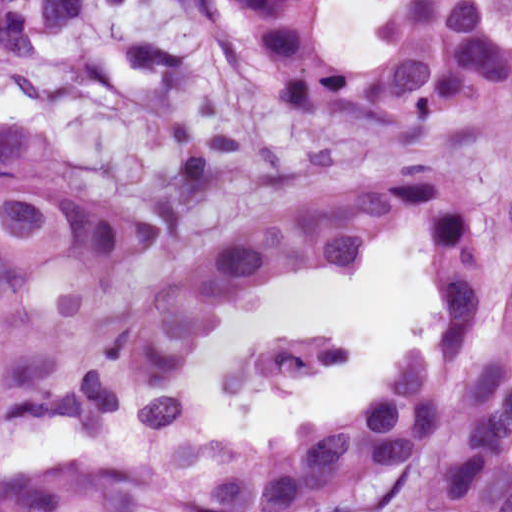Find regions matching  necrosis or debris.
I'll use <instances>...</instances> for the list:
<instances>
[{"label":"necrosis or debris","mask_w":512,"mask_h":512,"mask_svg":"<svg viewBox=\"0 0 512 512\" xmlns=\"http://www.w3.org/2000/svg\"><path fill=\"white\" fill-rule=\"evenodd\" d=\"M339 352L333 344L314 341H289L248 352L235 367V386L317 360Z\"/></svg>","instance_id":"4bbe7bcc"}]
</instances>
